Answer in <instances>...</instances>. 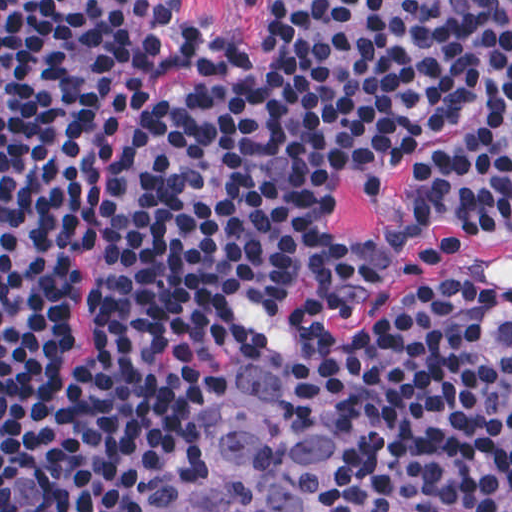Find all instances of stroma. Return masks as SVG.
<instances>
[{
  "label": "stroma",
  "instance_id": "35a3bbf8",
  "mask_svg": "<svg viewBox=\"0 0 512 512\" xmlns=\"http://www.w3.org/2000/svg\"><path fill=\"white\" fill-rule=\"evenodd\" d=\"M203 46L224 50L247 64H267L271 55L258 27L251 24L248 3L243 0H182ZM479 119L477 113L453 130L418 145L408 162L397 169L384 193L367 199L353 183L339 196V213L332 227L357 252L378 263L390 261L394 249H403L410 263L403 277L392 286L369 297L358 309L333 320L342 333H362L376 324L405 287L425 282L453 271L450 260H435L424 251L444 241L456 242L466 258L496 279H512V241L491 245L468 234L439 227L427 234H411L408 220L406 181L416 166L440 153L458 135ZM85 272L72 305V338L58 364V373L67 371L91 349V288L96 270V254L83 251ZM292 337L311 347L326 378V396L331 424V494L338 512H368L353 472V402L327 336L319 325L304 319H285L280 329L266 333L230 357L215 382L208 413L220 393L233 384L246 362L261 345L278 337ZM206 417V420H207ZM206 426V421H205ZM204 426V427H205ZM207 471L204 439L200 443L190 493L200 487Z\"/></svg>",
  "mask_w": 512,
  "mask_h": 512
}]
</instances>
